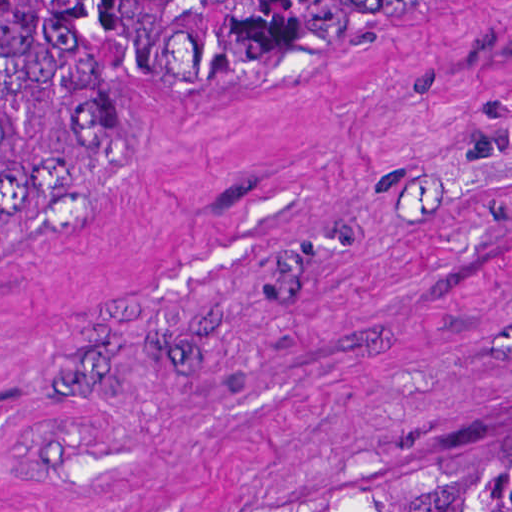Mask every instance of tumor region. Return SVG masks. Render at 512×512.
Here are the masks:
<instances>
[{"instance_id": "1", "label": "tumor region", "mask_w": 512, "mask_h": 512, "mask_svg": "<svg viewBox=\"0 0 512 512\" xmlns=\"http://www.w3.org/2000/svg\"><path fill=\"white\" fill-rule=\"evenodd\" d=\"M366 1L0 0V241ZM283 512H512V434L432 442Z\"/></svg>"}]
</instances>
